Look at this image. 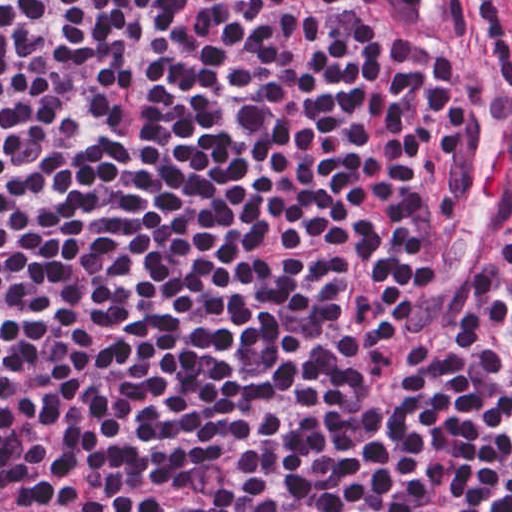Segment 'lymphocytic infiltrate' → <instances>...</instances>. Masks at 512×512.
Wrapping results in <instances>:
<instances>
[{
    "label": "lymphocytic infiltrate",
    "instance_id": "obj_1",
    "mask_svg": "<svg viewBox=\"0 0 512 512\" xmlns=\"http://www.w3.org/2000/svg\"><path fill=\"white\" fill-rule=\"evenodd\" d=\"M368 0H0V409Z\"/></svg>",
    "mask_w": 512,
    "mask_h": 512
}]
</instances>
